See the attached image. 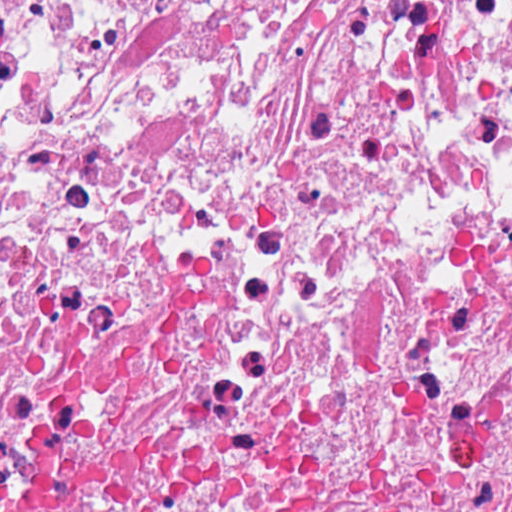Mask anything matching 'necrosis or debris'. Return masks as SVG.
I'll use <instances>...</instances> for the list:
<instances>
[{
  "label": "necrosis or debris",
  "instance_id": "1",
  "mask_svg": "<svg viewBox=\"0 0 512 512\" xmlns=\"http://www.w3.org/2000/svg\"><path fill=\"white\" fill-rule=\"evenodd\" d=\"M0 512H512V0H0Z\"/></svg>",
  "mask_w": 512,
  "mask_h": 512
}]
</instances>
